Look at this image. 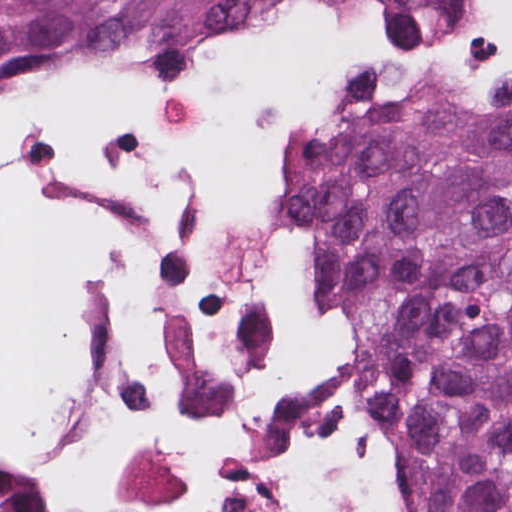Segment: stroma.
<instances>
[{
	"label": "stroma",
	"instance_id": "stroma-1",
	"mask_svg": "<svg viewBox=\"0 0 512 512\" xmlns=\"http://www.w3.org/2000/svg\"><path fill=\"white\" fill-rule=\"evenodd\" d=\"M496 0H484L470 15L426 37L391 39L345 0H255L218 22L204 41L196 62L213 66L222 49L263 29L283 27L298 19L323 16L392 44H444L460 41L492 20ZM35 54H99L83 51H38ZM481 89L461 84L428 63H408L382 90L362 104L393 99H437L477 93ZM289 154L318 116H282Z\"/></svg>",
	"mask_w": 512,
	"mask_h": 512
}]
</instances>
